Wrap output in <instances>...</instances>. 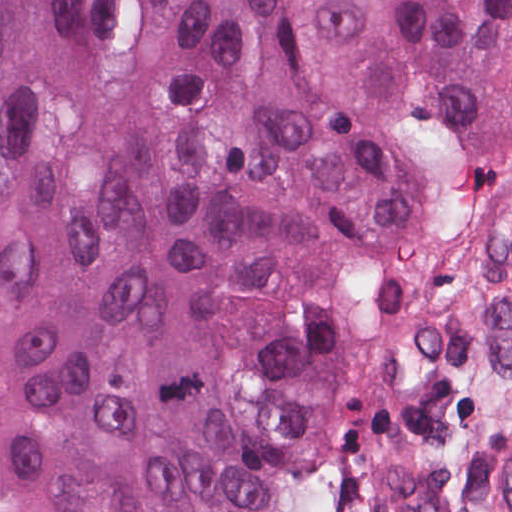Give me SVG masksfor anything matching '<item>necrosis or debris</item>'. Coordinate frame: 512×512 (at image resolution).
I'll use <instances>...</instances> for the list:
<instances>
[{"mask_svg": "<svg viewBox=\"0 0 512 512\" xmlns=\"http://www.w3.org/2000/svg\"><path fill=\"white\" fill-rule=\"evenodd\" d=\"M334 493L328 464L312 489L303 512H334Z\"/></svg>", "mask_w": 512, "mask_h": 512, "instance_id": "4bbe7bcc", "label": "necrosis or debris"}]
</instances>
